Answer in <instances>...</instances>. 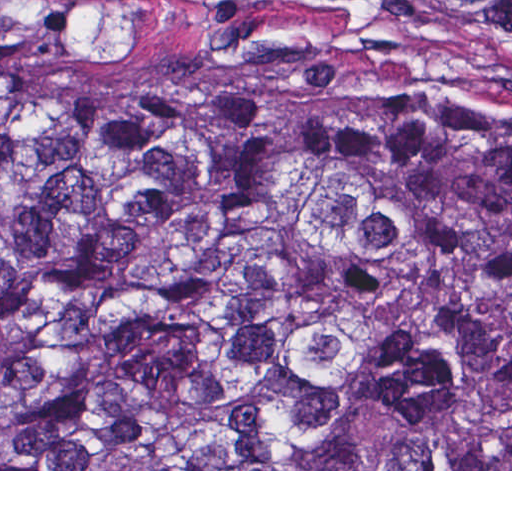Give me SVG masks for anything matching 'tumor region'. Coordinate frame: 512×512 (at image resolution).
<instances>
[{
  "instance_id": "1",
  "label": "tumor region",
  "mask_w": 512,
  "mask_h": 512,
  "mask_svg": "<svg viewBox=\"0 0 512 512\" xmlns=\"http://www.w3.org/2000/svg\"><path fill=\"white\" fill-rule=\"evenodd\" d=\"M508 96L367 124L0 25V469H512Z\"/></svg>"
}]
</instances>
